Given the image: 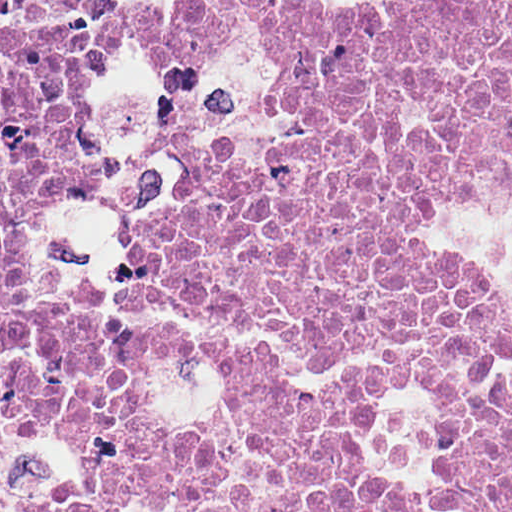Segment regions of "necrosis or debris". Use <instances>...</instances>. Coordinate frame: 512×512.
I'll return each instance as SVG.
<instances>
[{"label": "necrosis or debris", "instance_id": "obj_1", "mask_svg": "<svg viewBox=\"0 0 512 512\" xmlns=\"http://www.w3.org/2000/svg\"><path fill=\"white\" fill-rule=\"evenodd\" d=\"M0 512H512V0H0Z\"/></svg>", "mask_w": 512, "mask_h": 512}]
</instances>
